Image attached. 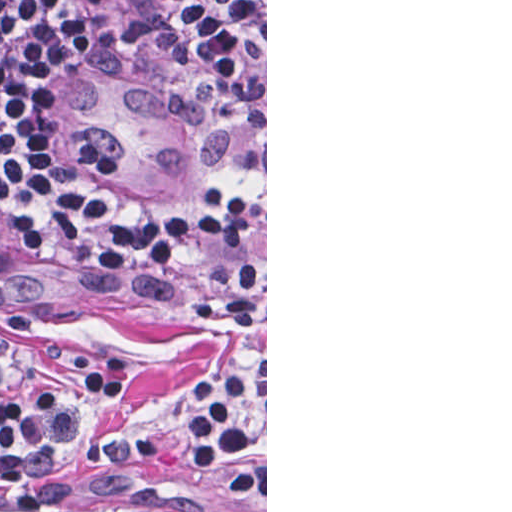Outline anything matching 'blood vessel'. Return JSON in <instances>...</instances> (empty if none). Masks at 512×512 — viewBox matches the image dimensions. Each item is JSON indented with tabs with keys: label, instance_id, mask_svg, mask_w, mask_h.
Returning a JSON list of instances; mask_svg holds the SVG:
<instances>
[{
	"label": "blood vessel",
	"instance_id": "blood-vessel-1",
	"mask_svg": "<svg viewBox=\"0 0 512 512\" xmlns=\"http://www.w3.org/2000/svg\"><path fill=\"white\" fill-rule=\"evenodd\" d=\"M84 106L131 177L195 181L234 164L240 104L159 0H58Z\"/></svg>",
	"mask_w": 512,
	"mask_h": 512
}]
</instances>
